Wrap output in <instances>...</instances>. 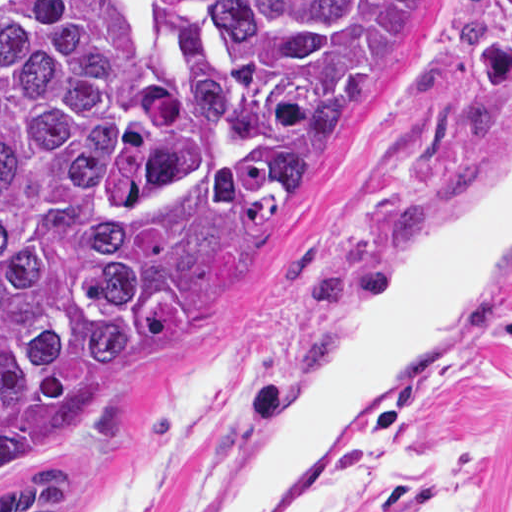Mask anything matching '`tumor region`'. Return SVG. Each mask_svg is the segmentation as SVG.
<instances>
[{
	"label": "tumor region",
	"mask_w": 512,
	"mask_h": 512,
	"mask_svg": "<svg viewBox=\"0 0 512 512\" xmlns=\"http://www.w3.org/2000/svg\"><path fill=\"white\" fill-rule=\"evenodd\" d=\"M435 0H0V512H86L179 324L329 295L265 226Z\"/></svg>",
	"instance_id": "obj_1"
}]
</instances>
